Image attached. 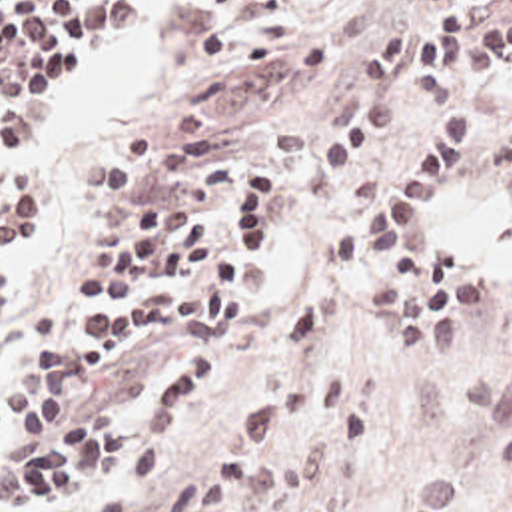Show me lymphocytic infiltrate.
I'll list each match as a JSON object with an SVG mask.
<instances>
[{"mask_svg":"<svg viewBox=\"0 0 512 512\" xmlns=\"http://www.w3.org/2000/svg\"><path fill=\"white\" fill-rule=\"evenodd\" d=\"M419 1L429 7L421 17L405 19L363 47L355 65L359 105L305 157L299 187L317 201L329 197L363 161L395 143L413 117L437 103L429 139L387 195L335 237L333 263L353 271L367 251L381 249V263L365 285L369 303L389 313L393 337L411 359L421 355V365H449L465 341V311L485 305L489 287L465 279L459 257L441 245L427 259L423 221L453 167L483 145L485 111L465 83L511 71L512 0ZM209 3L211 23L199 53L215 69L305 77L329 59V45L311 39L233 41L243 21L281 0ZM141 15V0H0V127L12 155L44 139L46 113L76 43L103 29L137 25ZM491 147L501 201L512 209V127ZM221 217L233 243L203 211L167 219L159 199L145 201L123 247V265L76 275L84 293H131L139 299L82 317L78 333L88 339L66 351L64 367L105 369L125 339L143 329L203 333L223 327L271 251L283 217V167L257 163L235 171ZM331 321L333 295L325 291L297 305L273 343L271 383L223 425L187 480L149 512H223L279 490L305 456L299 446L269 450L305 426L329 428L343 452L365 448L367 415L345 393L341 371L311 373L295 387ZM205 393L207 361L189 353L139 419L105 409L52 415L44 442L10 458L8 492L28 504H48L105 462L145 446L90 510L137 512L165 462L157 436L183 425Z\"/></svg>","mask_w":512,"mask_h":512,"instance_id":"obj_1","label":"lymphocytic infiltrate"}]
</instances>
